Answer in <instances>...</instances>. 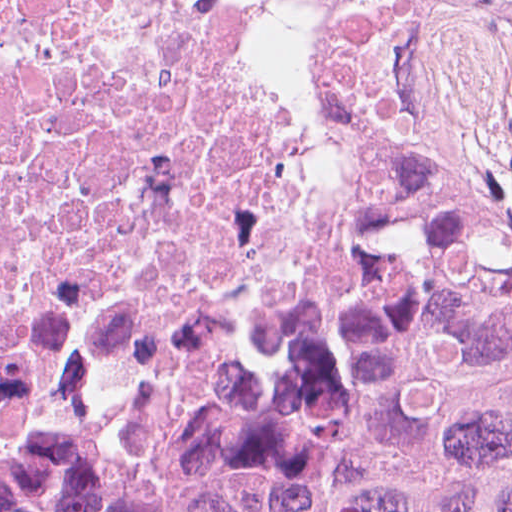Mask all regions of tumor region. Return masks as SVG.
I'll use <instances>...</instances> for the list:
<instances>
[{
	"instance_id": "e687c5a6",
	"label": "tumor region",
	"mask_w": 512,
	"mask_h": 512,
	"mask_svg": "<svg viewBox=\"0 0 512 512\" xmlns=\"http://www.w3.org/2000/svg\"><path fill=\"white\" fill-rule=\"evenodd\" d=\"M336 287L170 502L0 464V512H512V228L451 167L363 193Z\"/></svg>"
}]
</instances>
